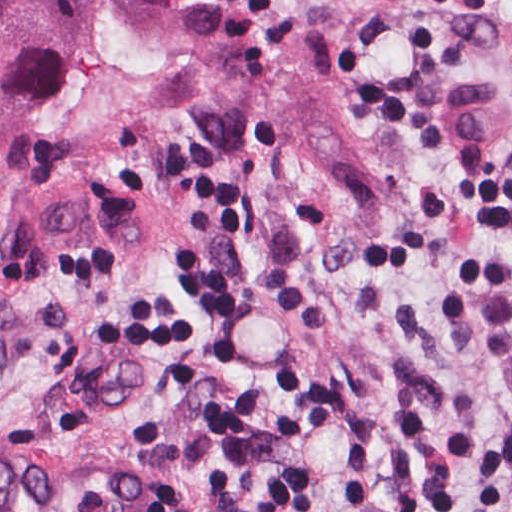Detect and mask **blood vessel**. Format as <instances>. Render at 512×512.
<instances>
[{"label":"blood vessel","instance_id":"1","mask_svg":"<svg viewBox=\"0 0 512 512\" xmlns=\"http://www.w3.org/2000/svg\"><path fill=\"white\" fill-rule=\"evenodd\" d=\"M142 210L117 187L73 175L36 190L10 220L22 274L90 248H140ZM156 482L26 440L3 444L0 512H158Z\"/></svg>","mask_w":512,"mask_h":512}]
</instances>
